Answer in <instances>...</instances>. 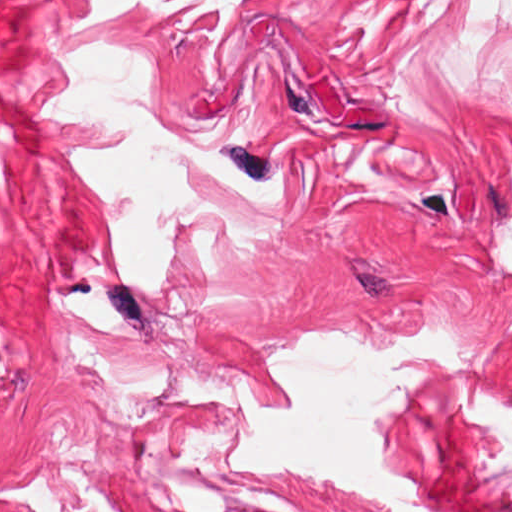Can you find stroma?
Listing matches in <instances>:
<instances>
[{
	"mask_svg": "<svg viewBox=\"0 0 512 512\" xmlns=\"http://www.w3.org/2000/svg\"><path fill=\"white\" fill-rule=\"evenodd\" d=\"M0 0V512H382L341 482L227 465L236 372L308 330L438 324L478 366L427 379L385 458L446 512H512V31L466 0L141 9ZM104 36L181 134L295 178L262 226L186 234L176 280L113 266L72 153L127 135L32 120L43 47Z\"/></svg>",
	"mask_w": 512,
	"mask_h": 512,
	"instance_id": "1",
	"label": "stroma"
}]
</instances>
